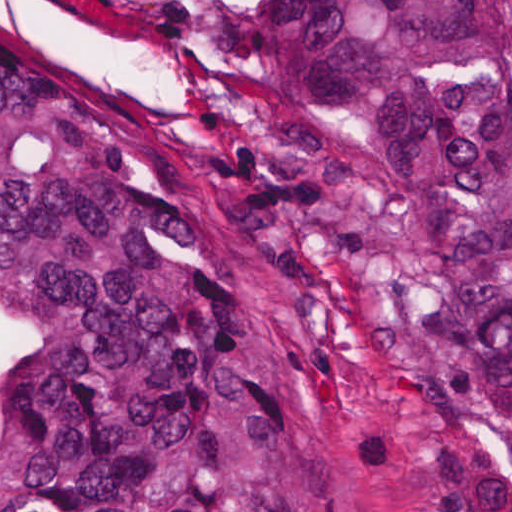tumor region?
I'll list each match as a JSON object with an SVG mask.
<instances>
[{
  "label": "tumor region",
  "instance_id": "tumor-region-1",
  "mask_svg": "<svg viewBox=\"0 0 512 512\" xmlns=\"http://www.w3.org/2000/svg\"><path fill=\"white\" fill-rule=\"evenodd\" d=\"M216 163L289 298L512 512V0H223ZM0 512H297L223 254L0 15Z\"/></svg>",
  "mask_w": 512,
  "mask_h": 512
}]
</instances>
